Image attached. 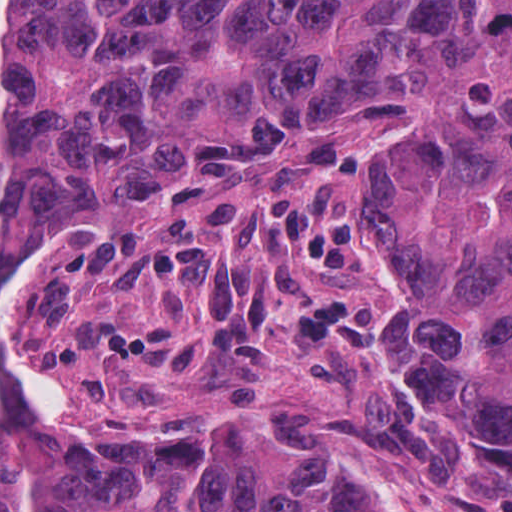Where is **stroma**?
Wrapping results in <instances>:
<instances>
[{
	"label": "stroma",
	"mask_w": 512,
	"mask_h": 512,
	"mask_svg": "<svg viewBox=\"0 0 512 512\" xmlns=\"http://www.w3.org/2000/svg\"><path fill=\"white\" fill-rule=\"evenodd\" d=\"M490 111L251 137L33 267L0 291L7 400L97 457L271 459L378 512H512V428L430 393L363 289L386 219ZM318 289L375 358L284 335Z\"/></svg>",
	"instance_id": "1"
}]
</instances>
